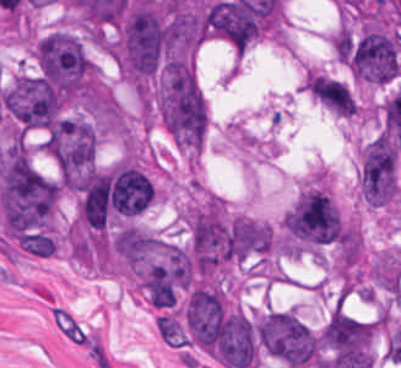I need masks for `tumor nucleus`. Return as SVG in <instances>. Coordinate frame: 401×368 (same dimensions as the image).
Returning <instances> with one entry per match:
<instances>
[{"mask_svg": "<svg viewBox=\"0 0 401 368\" xmlns=\"http://www.w3.org/2000/svg\"><path fill=\"white\" fill-rule=\"evenodd\" d=\"M148 302L172 309L193 281L192 250L145 229H126L117 252Z\"/></svg>", "mask_w": 401, "mask_h": 368, "instance_id": "1", "label": "tumor nucleus"}, {"mask_svg": "<svg viewBox=\"0 0 401 368\" xmlns=\"http://www.w3.org/2000/svg\"><path fill=\"white\" fill-rule=\"evenodd\" d=\"M155 325L165 342L172 345H184L183 329L175 318L168 315L156 314Z\"/></svg>", "mask_w": 401, "mask_h": 368, "instance_id": "8", "label": "tumor nucleus"}, {"mask_svg": "<svg viewBox=\"0 0 401 368\" xmlns=\"http://www.w3.org/2000/svg\"><path fill=\"white\" fill-rule=\"evenodd\" d=\"M311 95L334 114L349 117L355 112L353 92L337 78L315 73L311 77Z\"/></svg>", "mask_w": 401, "mask_h": 368, "instance_id": "7", "label": "tumor nucleus"}, {"mask_svg": "<svg viewBox=\"0 0 401 368\" xmlns=\"http://www.w3.org/2000/svg\"><path fill=\"white\" fill-rule=\"evenodd\" d=\"M290 250L340 243L343 225L331 196L311 185L294 200L282 220Z\"/></svg>", "mask_w": 401, "mask_h": 368, "instance_id": "3", "label": "tumor nucleus"}, {"mask_svg": "<svg viewBox=\"0 0 401 368\" xmlns=\"http://www.w3.org/2000/svg\"><path fill=\"white\" fill-rule=\"evenodd\" d=\"M355 76L371 81H388L401 72L398 34L394 30L367 27L351 57Z\"/></svg>", "mask_w": 401, "mask_h": 368, "instance_id": "5", "label": "tumor nucleus"}, {"mask_svg": "<svg viewBox=\"0 0 401 368\" xmlns=\"http://www.w3.org/2000/svg\"><path fill=\"white\" fill-rule=\"evenodd\" d=\"M259 345L290 368L310 364L317 354V335L295 314L267 310L259 315Z\"/></svg>", "mask_w": 401, "mask_h": 368, "instance_id": "4", "label": "tumor nucleus"}, {"mask_svg": "<svg viewBox=\"0 0 401 368\" xmlns=\"http://www.w3.org/2000/svg\"><path fill=\"white\" fill-rule=\"evenodd\" d=\"M376 325L377 321L339 307L319 332L318 341L333 357L372 353Z\"/></svg>", "mask_w": 401, "mask_h": 368, "instance_id": "6", "label": "tumor nucleus"}, {"mask_svg": "<svg viewBox=\"0 0 401 368\" xmlns=\"http://www.w3.org/2000/svg\"><path fill=\"white\" fill-rule=\"evenodd\" d=\"M34 57L38 74L60 92L86 94L96 90L95 66L76 34L52 30L37 41Z\"/></svg>", "mask_w": 401, "mask_h": 368, "instance_id": "2", "label": "tumor nucleus"}]
</instances>
